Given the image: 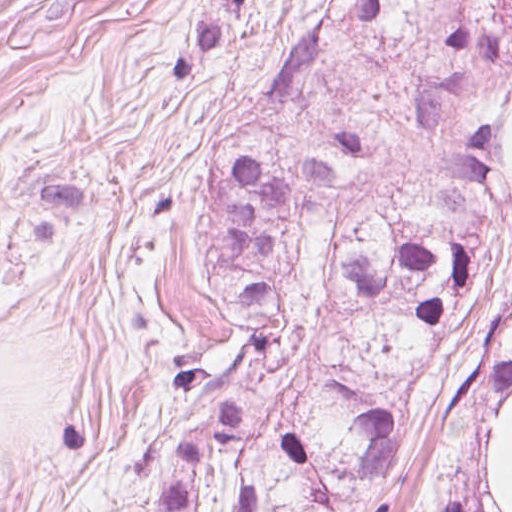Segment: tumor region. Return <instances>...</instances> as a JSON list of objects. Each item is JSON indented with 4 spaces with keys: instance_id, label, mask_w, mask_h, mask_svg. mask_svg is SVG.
Returning a JSON list of instances; mask_svg holds the SVG:
<instances>
[{
    "instance_id": "obj_1",
    "label": "tumor region",
    "mask_w": 512,
    "mask_h": 512,
    "mask_svg": "<svg viewBox=\"0 0 512 512\" xmlns=\"http://www.w3.org/2000/svg\"><path fill=\"white\" fill-rule=\"evenodd\" d=\"M216 0L138 95L184 80L235 15ZM332 24L276 53L225 118L318 94ZM410 186L361 222L311 309L291 305L310 209L349 182L357 130L259 172L219 143L193 241L243 334L185 391L156 512H512V0H446L420 61Z\"/></svg>"
}]
</instances>
